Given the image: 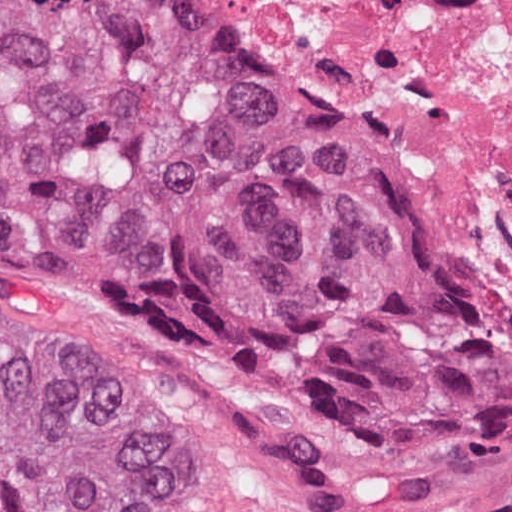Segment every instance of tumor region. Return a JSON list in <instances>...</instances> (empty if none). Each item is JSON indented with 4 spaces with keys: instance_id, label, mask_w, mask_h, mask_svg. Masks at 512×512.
<instances>
[{
    "instance_id": "1",
    "label": "tumor region",
    "mask_w": 512,
    "mask_h": 512,
    "mask_svg": "<svg viewBox=\"0 0 512 512\" xmlns=\"http://www.w3.org/2000/svg\"><path fill=\"white\" fill-rule=\"evenodd\" d=\"M0 248L512 465V355L334 106L203 0H0ZM156 414L0 304V512H172Z\"/></svg>"
}]
</instances>
